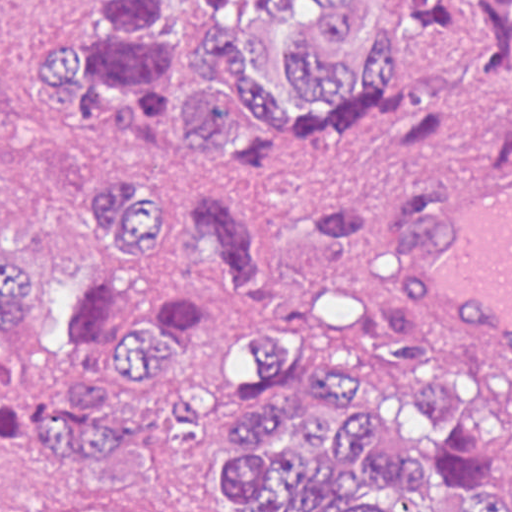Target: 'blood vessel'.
<instances>
[{"label":"blood vessel","instance_id":"1","mask_svg":"<svg viewBox=\"0 0 512 512\" xmlns=\"http://www.w3.org/2000/svg\"><path fill=\"white\" fill-rule=\"evenodd\" d=\"M371 262L424 333L512 376V177L427 188Z\"/></svg>","mask_w":512,"mask_h":512}]
</instances>
